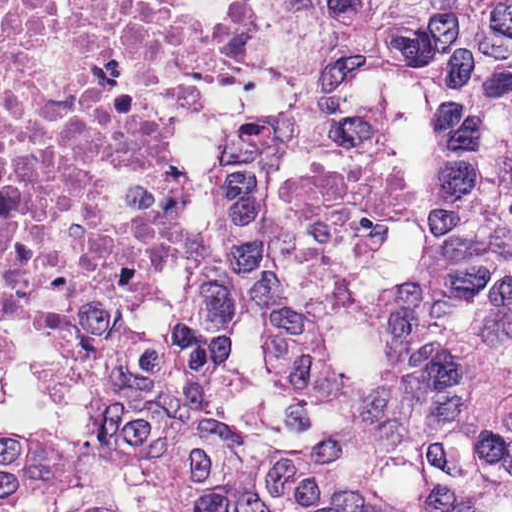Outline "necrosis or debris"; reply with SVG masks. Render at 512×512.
<instances>
[{"instance_id":"necrosis-or-debris-1","label":"necrosis or debris","mask_w":512,"mask_h":512,"mask_svg":"<svg viewBox=\"0 0 512 512\" xmlns=\"http://www.w3.org/2000/svg\"><path fill=\"white\" fill-rule=\"evenodd\" d=\"M260 0H0V232L188 149L160 99L263 67Z\"/></svg>"}]
</instances>
